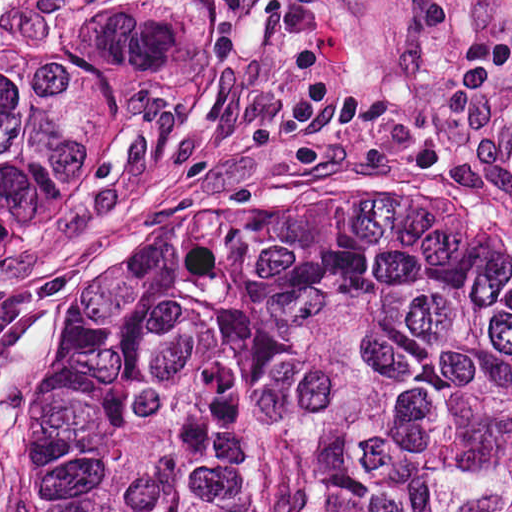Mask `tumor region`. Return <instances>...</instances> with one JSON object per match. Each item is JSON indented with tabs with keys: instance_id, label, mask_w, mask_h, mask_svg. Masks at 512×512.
I'll use <instances>...</instances> for the list:
<instances>
[{
	"instance_id": "tumor-region-1",
	"label": "tumor region",
	"mask_w": 512,
	"mask_h": 512,
	"mask_svg": "<svg viewBox=\"0 0 512 512\" xmlns=\"http://www.w3.org/2000/svg\"><path fill=\"white\" fill-rule=\"evenodd\" d=\"M168 34L0 2V258ZM13 379L20 512H512V241L456 189L95 241Z\"/></svg>"
}]
</instances>
